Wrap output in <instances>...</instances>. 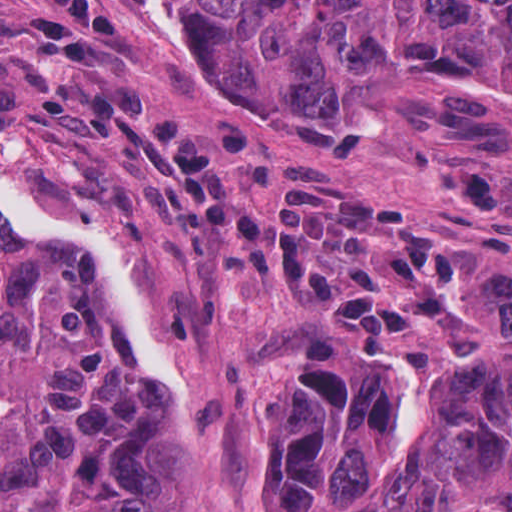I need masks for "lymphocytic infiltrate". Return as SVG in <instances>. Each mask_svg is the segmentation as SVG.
<instances>
[{"label":"lymphocytic infiltrate","instance_id":"lymphocytic-infiltrate-1","mask_svg":"<svg viewBox=\"0 0 512 512\" xmlns=\"http://www.w3.org/2000/svg\"><path fill=\"white\" fill-rule=\"evenodd\" d=\"M117 36L113 0H25L11 29L39 81V113L73 114L81 144L128 156L177 210L179 247L200 278L304 295L371 350L421 337L465 305L474 259L374 183L282 157L257 215L238 188L251 133L233 119L182 131L140 78H105Z\"/></svg>","mask_w":512,"mask_h":512}]
</instances>
